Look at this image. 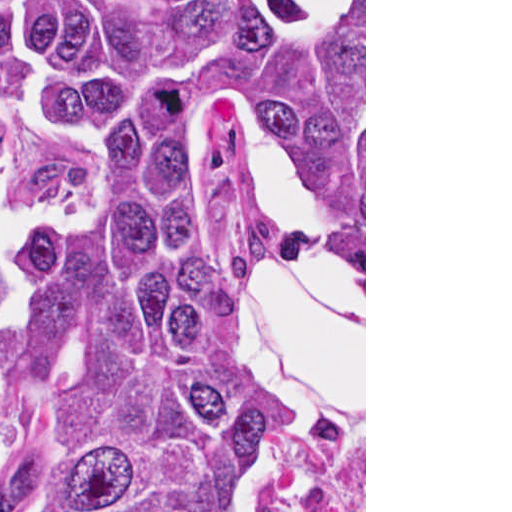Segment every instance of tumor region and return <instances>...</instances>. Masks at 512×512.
<instances>
[{
  "label": "tumor region",
  "mask_w": 512,
  "mask_h": 512,
  "mask_svg": "<svg viewBox=\"0 0 512 512\" xmlns=\"http://www.w3.org/2000/svg\"><path fill=\"white\" fill-rule=\"evenodd\" d=\"M253 112L364 248V1H0V512L365 504V408L287 439L216 318Z\"/></svg>",
  "instance_id": "obj_1"
}]
</instances>
